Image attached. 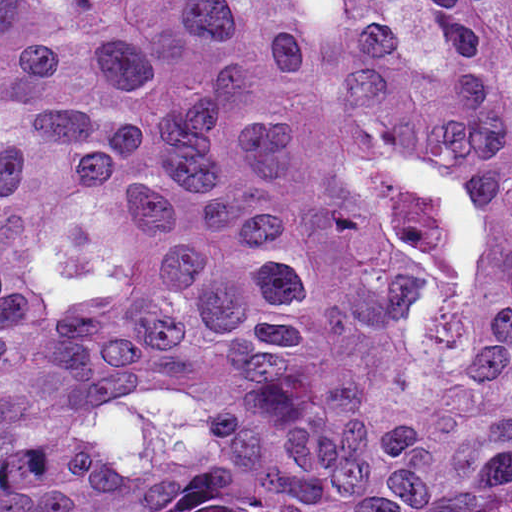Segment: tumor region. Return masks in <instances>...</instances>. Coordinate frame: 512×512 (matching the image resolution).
Here are the masks:
<instances>
[{"label":"tumor region","instance_id":"e687c5a6","mask_svg":"<svg viewBox=\"0 0 512 512\" xmlns=\"http://www.w3.org/2000/svg\"><path fill=\"white\" fill-rule=\"evenodd\" d=\"M0 512H512V0H0Z\"/></svg>","mask_w":512,"mask_h":512}]
</instances>
